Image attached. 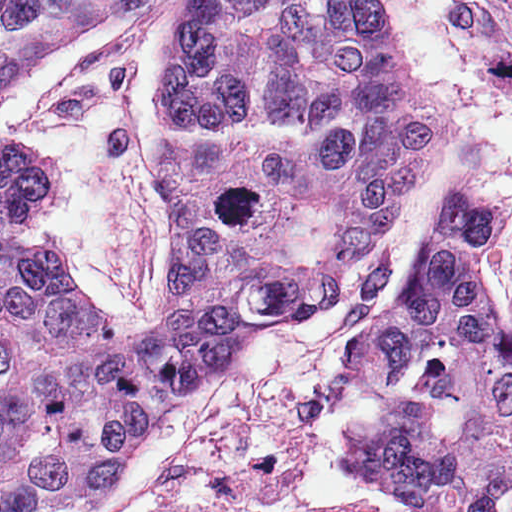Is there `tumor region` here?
Here are the masks:
<instances>
[{
  "mask_svg": "<svg viewBox=\"0 0 512 512\" xmlns=\"http://www.w3.org/2000/svg\"><path fill=\"white\" fill-rule=\"evenodd\" d=\"M159 1L0 0V125L25 77L134 29ZM456 131L391 0L189 6L147 111L187 237L158 323L70 282L33 222L54 167L0 152V512H102L164 413L326 308ZM496 216L459 189L442 200L411 280L349 346L378 410L358 464L414 512H512V334L486 254Z\"/></svg>",
  "mask_w": 512,
  "mask_h": 512,
  "instance_id": "tumor-region-1",
  "label": "tumor region"
}]
</instances>
